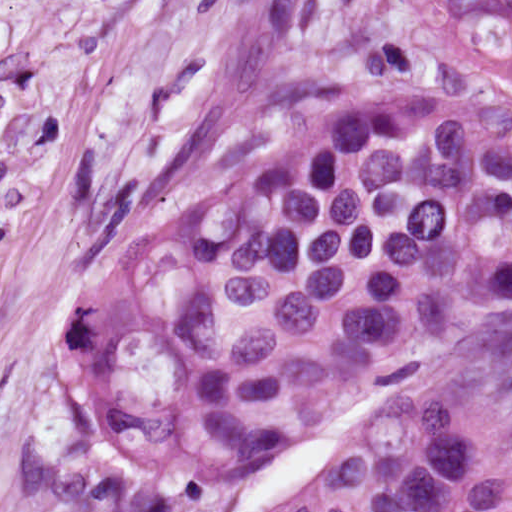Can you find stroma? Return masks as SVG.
I'll return each mask as SVG.
<instances>
[{
	"label": "stroma",
	"instance_id": "stroma-1",
	"mask_svg": "<svg viewBox=\"0 0 512 512\" xmlns=\"http://www.w3.org/2000/svg\"><path fill=\"white\" fill-rule=\"evenodd\" d=\"M431 0H0V484L34 337L124 246L371 86L497 77ZM356 413L294 436L180 512H296ZM462 436L512 449V368L454 394Z\"/></svg>",
	"mask_w": 512,
	"mask_h": 512
}]
</instances>
